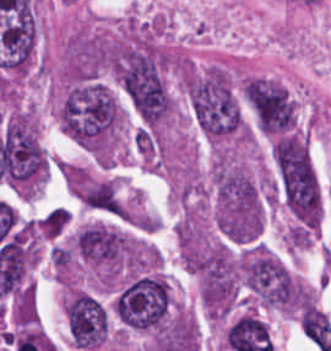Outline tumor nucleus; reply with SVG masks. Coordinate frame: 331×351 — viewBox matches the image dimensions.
Masks as SVG:
<instances>
[{"instance_id":"obj_2","label":"tumor nucleus","mask_w":331,"mask_h":351,"mask_svg":"<svg viewBox=\"0 0 331 351\" xmlns=\"http://www.w3.org/2000/svg\"><path fill=\"white\" fill-rule=\"evenodd\" d=\"M170 307V288L160 271L138 274L118 290L112 309L127 328L145 330L159 328Z\"/></svg>"},{"instance_id":"obj_1","label":"tumor nucleus","mask_w":331,"mask_h":351,"mask_svg":"<svg viewBox=\"0 0 331 351\" xmlns=\"http://www.w3.org/2000/svg\"><path fill=\"white\" fill-rule=\"evenodd\" d=\"M112 67L133 109L144 119H163L172 105L165 50L147 34H134L113 45Z\"/></svg>"}]
</instances>
